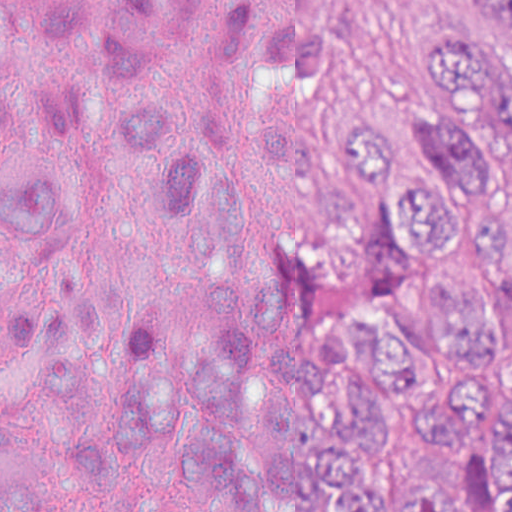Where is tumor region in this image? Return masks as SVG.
Segmentation results:
<instances>
[{
	"label": "tumor region",
	"mask_w": 512,
	"mask_h": 512,
	"mask_svg": "<svg viewBox=\"0 0 512 512\" xmlns=\"http://www.w3.org/2000/svg\"><path fill=\"white\" fill-rule=\"evenodd\" d=\"M477 2L489 25L474 40H434L419 119L355 115L343 131L344 212L304 229L320 312L291 346L292 402L272 400L266 343L293 287L239 268L264 199L336 185V152L277 104L323 70L317 24L237 4L193 33H132L104 0L0 4V44L48 45L168 253L213 275L184 335L128 307L110 432L74 424L38 459L36 421L84 394L112 301L91 272L17 278L2 306L0 512H64L70 487L125 484L119 445L216 512H512V0ZM62 229L63 199L0 166V241L19 255Z\"/></svg>",
	"instance_id": "obj_1"
}]
</instances>
